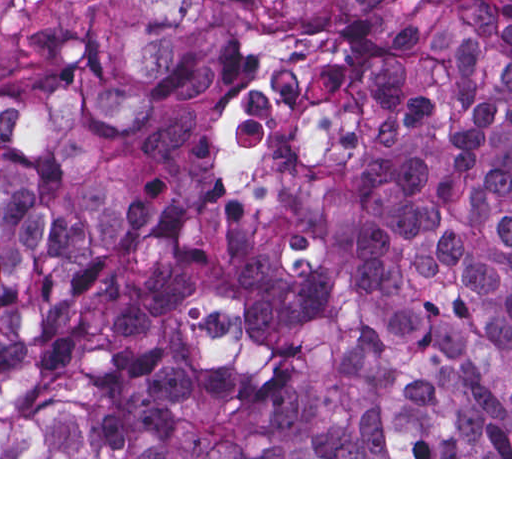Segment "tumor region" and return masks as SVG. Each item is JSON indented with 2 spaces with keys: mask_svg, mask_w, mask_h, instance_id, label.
<instances>
[{
  "mask_svg": "<svg viewBox=\"0 0 512 512\" xmlns=\"http://www.w3.org/2000/svg\"><path fill=\"white\" fill-rule=\"evenodd\" d=\"M0 457H512V0H0Z\"/></svg>",
  "mask_w": 512,
  "mask_h": 512,
  "instance_id": "tumor-region-1",
  "label": "tumor region"
}]
</instances>
